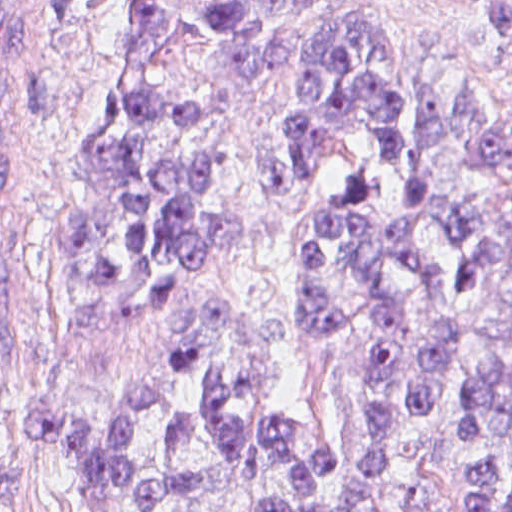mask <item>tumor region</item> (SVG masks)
<instances>
[{"label":"tumor region","instance_id":"obj_1","mask_svg":"<svg viewBox=\"0 0 512 512\" xmlns=\"http://www.w3.org/2000/svg\"><path fill=\"white\" fill-rule=\"evenodd\" d=\"M485 33L512 26V1H465ZM201 3L218 45L212 72L246 88L287 78L280 152L263 164V190L278 206L314 179L337 145L363 127V154L307 231L301 273L302 331L326 346L352 317L335 280L363 295L371 319L368 446L340 495L319 492L347 464L349 444L318 435L295 453L297 427L269 417L252 435L214 368L201 405L221 447L238 462L283 466L293 486L263 512H355L390 461L399 435L439 403L457 366L450 324L425 313L452 309L474 334L476 369L457 412L472 442L512 412V105L491 104L433 67L395 70L377 1H185L107 78L87 117L62 232L71 278L173 299L234 231L207 202L209 144L191 125L192 90L164 93L149 79L155 49L187 5ZM6 90L0 74V512H10V463L20 417L6 375V294L48 279V256L17 222H4ZM181 324L170 338H179ZM202 357L194 342L89 408H33L59 449L87 512H150L202 486L193 469L163 472L190 440L191 415L172 412L149 448L136 431L165 401L159 374ZM384 502L435 512L434 488L406 484ZM191 512V511H180ZM462 512H512V462L467 469Z\"/></svg>","mask_w":512,"mask_h":512}]
</instances>
